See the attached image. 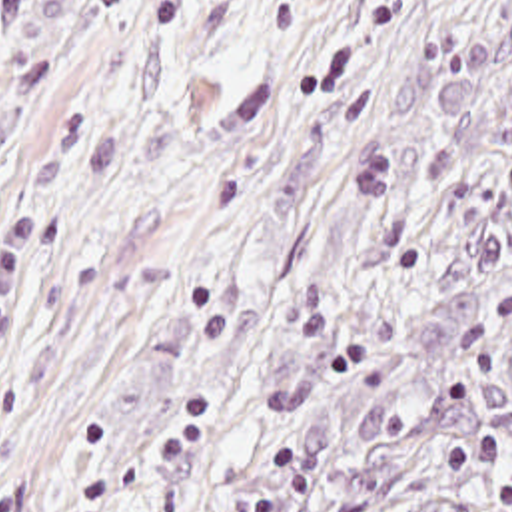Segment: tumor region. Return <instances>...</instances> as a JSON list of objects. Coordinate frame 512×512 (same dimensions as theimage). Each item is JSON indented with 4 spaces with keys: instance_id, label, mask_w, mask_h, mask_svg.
<instances>
[{
    "instance_id": "obj_1",
    "label": "tumor region",
    "mask_w": 512,
    "mask_h": 512,
    "mask_svg": "<svg viewBox=\"0 0 512 512\" xmlns=\"http://www.w3.org/2000/svg\"><path fill=\"white\" fill-rule=\"evenodd\" d=\"M153 512H512V77L301 289Z\"/></svg>"
}]
</instances>
